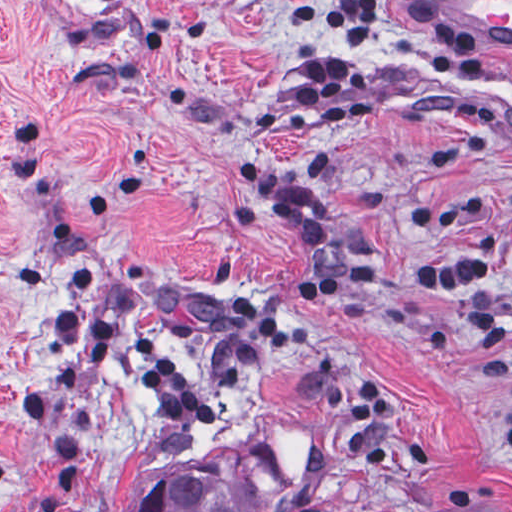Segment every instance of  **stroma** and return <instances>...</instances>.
I'll list each match as a JSON object with an SVG mask.
<instances>
[{"label":"stroma","instance_id":"35a3bbf8","mask_svg":"<svg viewBox=\"0 0 512 512\" xmlns=\"http://www.w3.org/2000/svg\"><path fill=\"white\" fill-rule=\"evenodd\" d=\"M420 1L483 67L349 56L370 115L322 128L291 95L292 64L342 55L318 0H0V512H128L203 463L279 489L266 512H512V343L467 325L512 318V0ZM246 155L309 188L367 283L291 298L313 254L233 178ZM481 230L484 282H409ZM234 293L290 333L242 389ZM82 304L153 333L176 387L116 355L85 374L57 330ZM367 373L394 421L351 420Z\"/></svg>","mask_w":512,"mask_h":512}]
</instances>
